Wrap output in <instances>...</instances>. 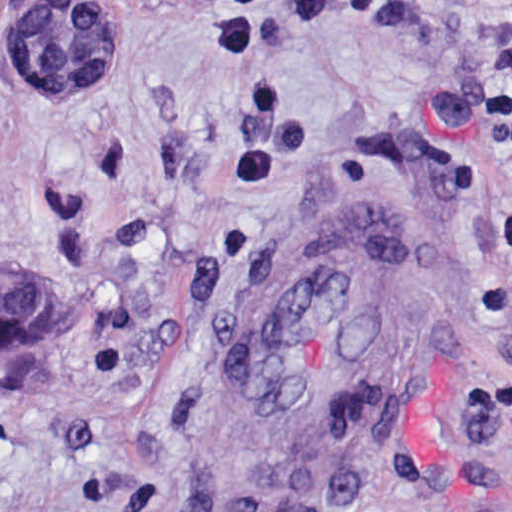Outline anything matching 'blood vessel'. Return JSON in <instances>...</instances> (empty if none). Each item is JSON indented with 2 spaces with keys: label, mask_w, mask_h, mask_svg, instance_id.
I'll list each match as a JSON object with an SVG mask.
<instances>
[{
  "label": "blood vessel",
  "mask_w": 512,
  "mask_h": 512,
  "mask_svg": "<svg viewBox=\"0 0 512 512\" xmlns=\"http://www.w3.org/2000/svg\"><path fill=\"white\" fill-rule=\"evenodd\" d=\"M380 206L317 215L257 281L203 395V512L331 505L377 447L424 328V264Z\"/></svg>",
  "instance_id": "blood-vessel-1"
}]
</instances>
